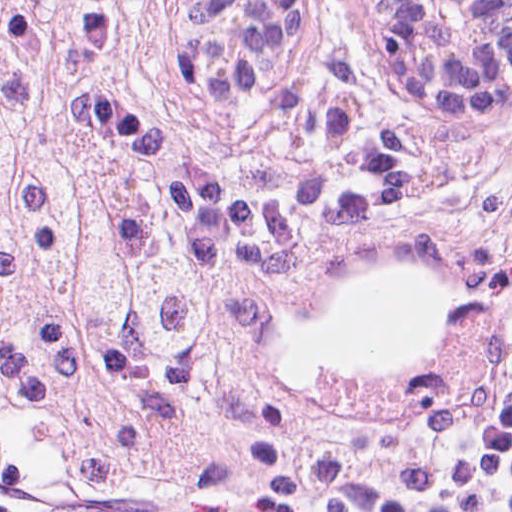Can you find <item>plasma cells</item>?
I'll return each mask as SVG.
<instances>
[{
	"label": "plasma cells",
	"mask_w": 512,
	"mask_h": 512,
	"mask_svg": "<svg viewBox=\"0 0 512 512\" xmlns=\"http://www.w3.org/2000/svg\"><path fill=\"white\" fill-rule=\"evenodd\" d=\"M483 165L512 197V91ZM401 433L449 512H512V314L458 349L414 394Z\"/></svg>",
	"instance_id": "obj_1"
}]
</instances>
